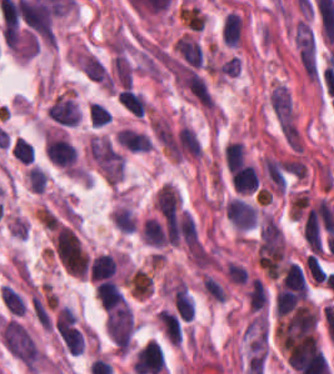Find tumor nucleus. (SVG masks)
Masks as SVG:
<instances>
[{"label":"tumor nucleus","instance_id":"obj_1","mask_svg":"<svg viewBox=\"0 0 334 374\" xmlns=\"http://www.w3.org/2000/svg\"><path fill=\"white\" fill-rule=\"evenodd\" d=\"M77 64L84 75L101 87L112 88L110 75L104 64L86 49L75 54Z\"/></svg>","mask_w":334,"mask_h":374}]
</instances>
